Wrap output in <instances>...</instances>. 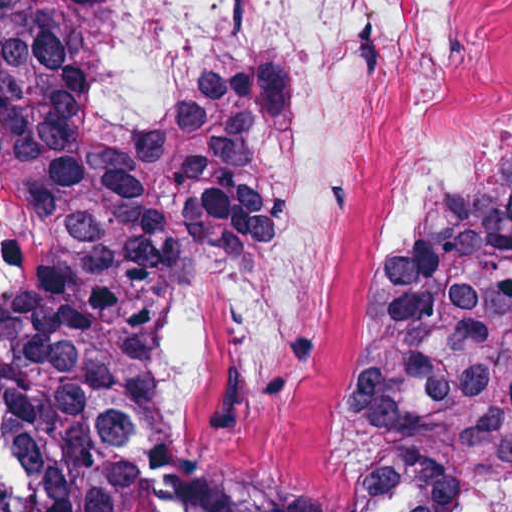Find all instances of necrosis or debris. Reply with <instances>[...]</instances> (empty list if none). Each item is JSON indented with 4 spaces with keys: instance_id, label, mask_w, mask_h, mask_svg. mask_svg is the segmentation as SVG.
<instances>
[{
    "instance_id": "4bbe7bcc",
    "label": "necrosis or debris",
    "mask_w": 512,
    "mask_h": 512,
    "mask_svg": "<svg viewBox=\"0 0 512 512\" xmlns=\"http://www.w3.org/2000/svg\"><path fill=\"white\" fill-rule=\"evenodd\" d=\"M265 61L310 68L280 209L167 318L180 420L245 468L338 449L349 352L429 216L512 147V0H82L52 84L123 128Z\"/></svg>"
}]
</instances>
